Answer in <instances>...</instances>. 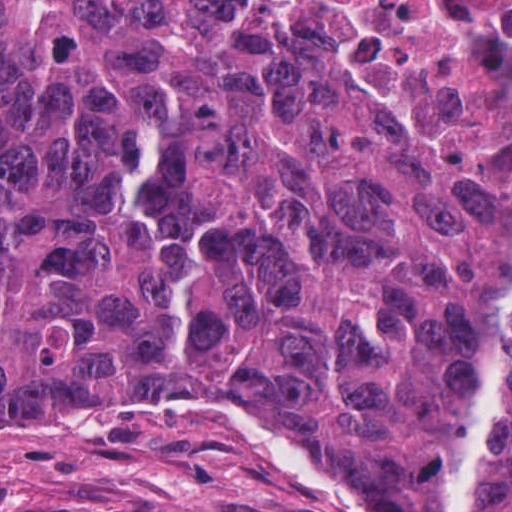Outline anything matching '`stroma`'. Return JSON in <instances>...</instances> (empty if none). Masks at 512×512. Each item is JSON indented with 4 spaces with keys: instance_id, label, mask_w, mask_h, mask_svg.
<instances>
[{
    "instance_id": "35a3bbf8",
    "label": "stroma",
    "mask_w": 512,
    "mask_h": 512,
    "mask_svg": "<svg viewBox=\"0 0 512 512\" xmlns=\"http://www.w3.org/2000/svg\"><path fill=\"white\" fill-rule=\"evenodd\" d=\"M0 512H268L141 411L0 415Z\"/></svg>"
}]
</instances>
